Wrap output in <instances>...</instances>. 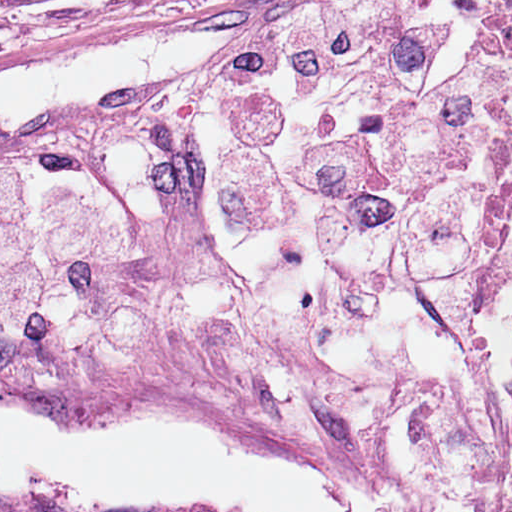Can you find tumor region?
<instances>
[{"label":"tumor region","instance_id":"1","mask_svg":"<svg viewBox=\"0 0 512 512\" xmlns=\"http://www.w3.org/2000/svg\"><path fill=\"white\" fill-rule=\"evenodd\" d=\"M0 512H48L33 504L0 500Z\"/></svg>","mask_w":512,"mask_h":512}]
</instances>
